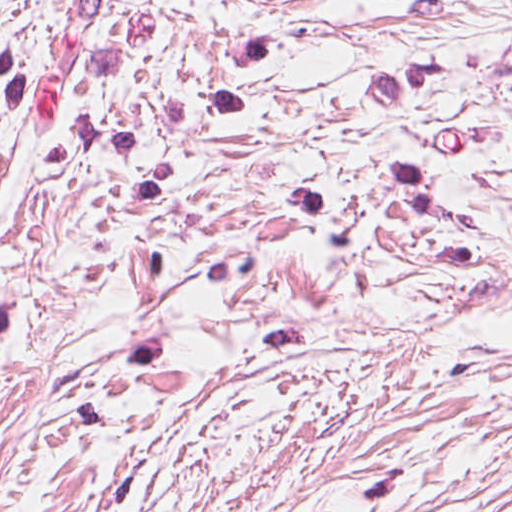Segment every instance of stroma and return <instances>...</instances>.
I'll use <instances>...</instances> for the list:
<instances>
[{
    "label": "stroma",
    "instance_id": "stroma-1",
    "mask_svg": "<svg viewBox=\"0 0 512 512\" xmlns=\"http://www.w3.org/2000/svg\"><path fill=\"white\" fill-rule=\"evenodd\" d=\"M0 512H512V0H0Z\"/></svg>",
    "mask_w": 512,
    "mask_h": 512
}]
</instances>
